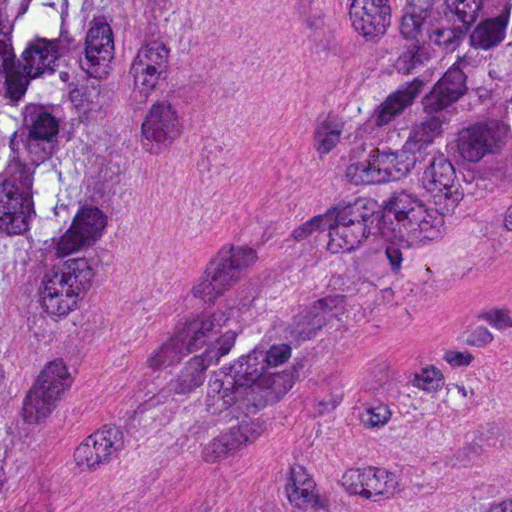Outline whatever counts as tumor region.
<instances>
[{
  "label": "tumor region",
  "mask_w": 512,
  "mask_h": 512,
  "mask_svg": "<svg viewBox=\"0 0 512 512\" xmlns=\"http://www.w3.org/2000/svg\"><path fill=\"white\" fill-rule=\"evenodd\" d=\"M147 1H0V339L110 300L113 190L155 148L127 124L124 24ZM389 10L387 67L223 269L175 399L255 402L375 291L512 219V1Z\"/></svg>",
  "instance_id": "e687c5a6"
}]
</instances>
